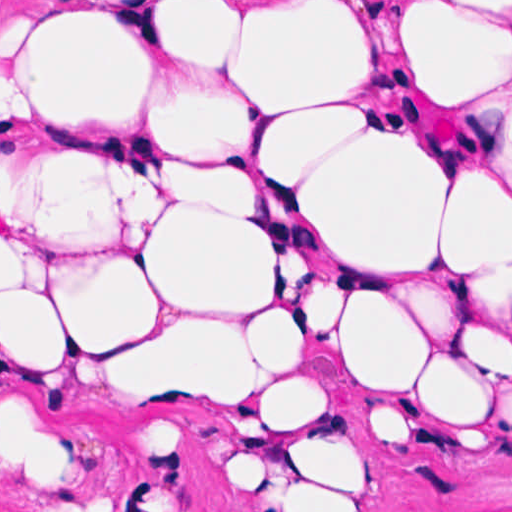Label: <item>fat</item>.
I'll list each match as a JSON object with an SVG mask.
<instances>
[{
  "instance_id": "1",
  "label": "fat",
  "mask_w": 512,
  "mask_h": 512,
  "mask_svg": "<svg viewBox=\"0 0 512 512\" xmlns=\"http://www.w3.org/2000/svg\"><path fill=\"white\" fill-rule=\"evenodd\" d=\"M15 28L18 356L218 403L249 512H339L349 481L300 338L351 381L486 420L512 385V1H0ZM304 242L330 257L311 307ZM74 466L64 421L0 400V467L36 512Z\"/></svg>"
}]
</instances>
